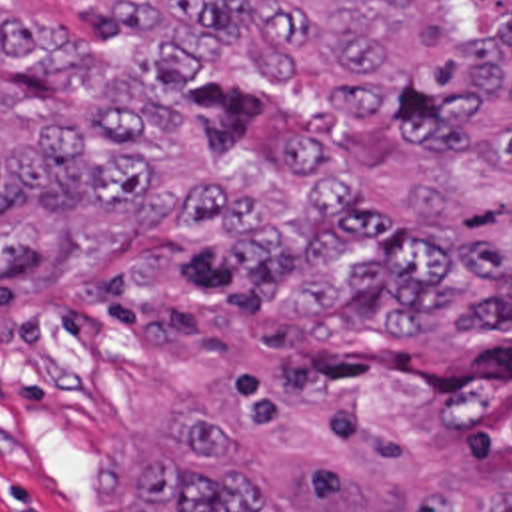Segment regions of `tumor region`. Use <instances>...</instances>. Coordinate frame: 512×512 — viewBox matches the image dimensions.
<instances>
[{
  "label": "tumor region",
  "mask_w": 512,
  "mask_h": 512,
  "mask_svg": "<svg viewBox=\"0 0 512 512\" xmlns=\"http://www.w3.org/2000/svg\"><path fill=\"white\" fill-rule=\"evenodd\" d=\"M109 3L125 39L0 0V247L167 209L179 241L287 321L441 341L427 430L512 490V0ZM299 95L357 133L271 127L219 157L187 135ZM135 486L131 512H267L209 418ZM413 512L467 508L429 488Z\"/></svg>",
  "instance_id": "tumor-region-1"
}]
</instances>
